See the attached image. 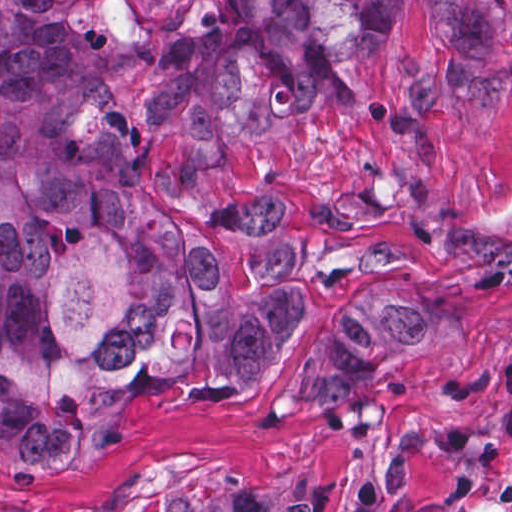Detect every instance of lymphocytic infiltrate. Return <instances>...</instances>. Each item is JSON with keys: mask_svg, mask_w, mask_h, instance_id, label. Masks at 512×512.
<instances>
[{"mask_svg": "<svg viewBox=\"0 0 512 512\" xmlns=\"http://www.w3.org/2000/svg\"><path fill=\"white\" fill-rule=\"evenodd\" d=\"M349 512H402L375 491L356 494ZM425 512H493L478 503H451Z\"/></svg>", "mask_w": 512, "mask_h": 512, "instance_id": "1", "label": "lymphocytic infiltrate"}]
</instances>
